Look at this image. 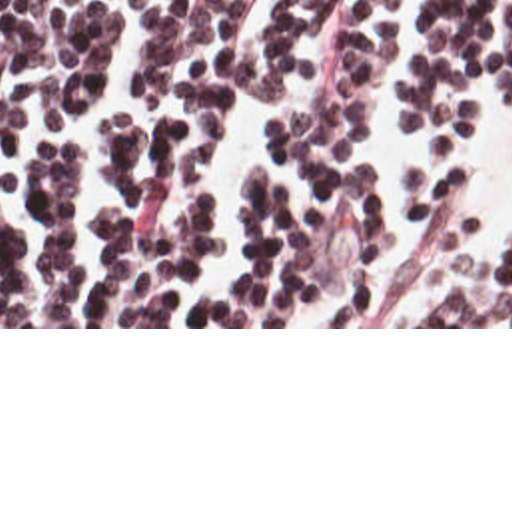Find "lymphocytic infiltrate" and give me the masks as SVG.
<instances>
[{"mask_svg":"<svg viewBox=\"0 0 512 512\" xmlns=\"http://www.w3.org/2000/svg\"><path fill=\"white\" fill-rule=\"evenodd\" d=\"M0 0V327H512V243L481 253L473 165L413 163L417 229L385 235L369 147L391 0ZM512 99V0H425L395 113L457 125ZM289 87V91H287ZM241 173L243 261L203 187L227 111L263 107Z\"/></svg>","mask_w":512,"mask_h":512,"instance_id":"obj_1","label":"lymphocytic infiltrate"}]
</instances>
